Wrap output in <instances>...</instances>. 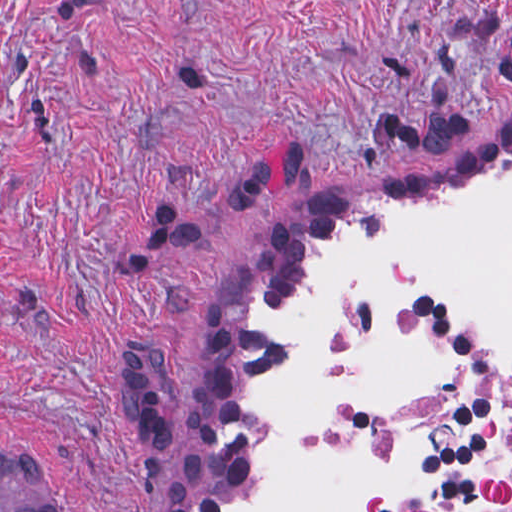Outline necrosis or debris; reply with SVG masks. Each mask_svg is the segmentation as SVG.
<instances>
[{"label": "necrosis or debris", "instance_id": "1", "mask_svg": "<svg viewBox=\"0 0 512 512\" xmlns=\"http://www.w3.org/2000/svg\"><path fill=\"white\" fill-rule=\"evenodd\" d=\"M405 323L432 346L440 380L413 399H343L327 418L339 439L410 454L421 481L377 512H512V346L482 340L456 295L420 288Z\"/></svg>", "mask_w": 512, "mask_h": 512}]
</instances>
